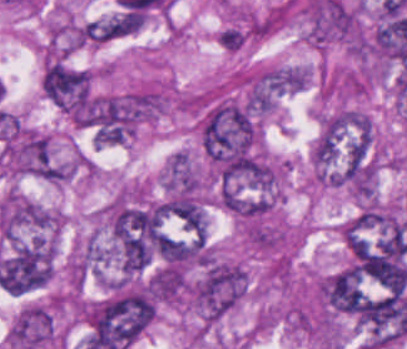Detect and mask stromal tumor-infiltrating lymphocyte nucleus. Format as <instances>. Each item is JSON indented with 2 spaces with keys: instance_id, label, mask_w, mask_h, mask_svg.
Masks as SVG:
<instances>
[{
  "instance_id": "obj_1",
  "label": "stromal tumor-infiltrating lymphocyte nucleus",
  "mask_w": 407,
  "mask_h": 349,
  "mask_svg": "<svg viewBox=\"0 0 407 349\" xmlns=\"http://www.w3.org/2000/svg\"><path fill=\"white\" fill-rule=\"evenodd\" d=\"M247 39V31L237 25L229 24L218 29L216 42L224 50L235 51L242 46Z\"/></svg>"
}]
</instances>
